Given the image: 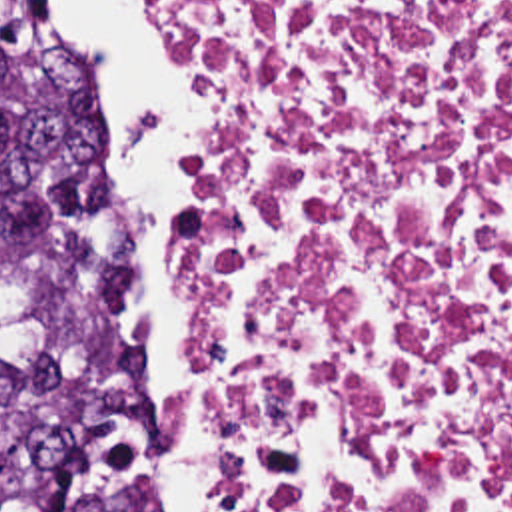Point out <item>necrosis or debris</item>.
I'll return each mask as SVG.
<instances>
[{
    "label": "necrosis or debris",
    "mask_w": 512,
    "mask_h": 512,
    "mask_svg": "<svg viewBox=\"0 0 512 512\" xmlns=\"http://www.w3.org/2000/svg\"><path fill=\"white\" fill-rule=\"evenodd\" d=\"M158 2L214 512H512V0Z\"/></svg>",
    "instance_id": "1"
}]
</instances>
